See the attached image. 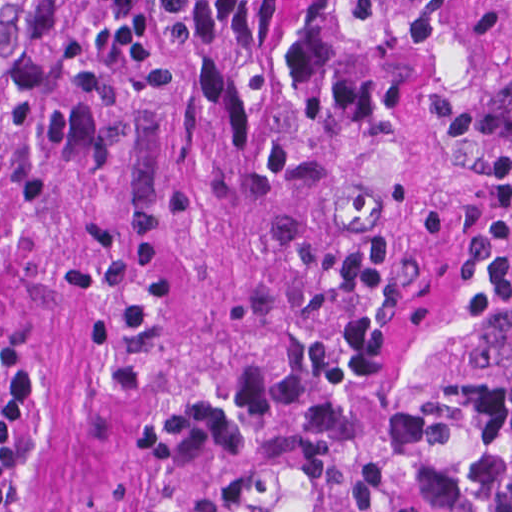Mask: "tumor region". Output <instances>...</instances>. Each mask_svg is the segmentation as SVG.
Wrapping results in <instances>:
<instances>
[{
	"mask_svg": "<svg viewBox=\"0 0 512 512\" xmlns=\"http://www.w3.org/2000/svg\"><path fill=\"white\" fill-rule=\"evenodd\" d=\"M422 69L423 0H0V512H384Z\"/></svg>",
	"mask_w": 512,
	"mask_h": 512,
	"instance_id": "obj_1",
	"label": "tumor region"
}]
</instances>
